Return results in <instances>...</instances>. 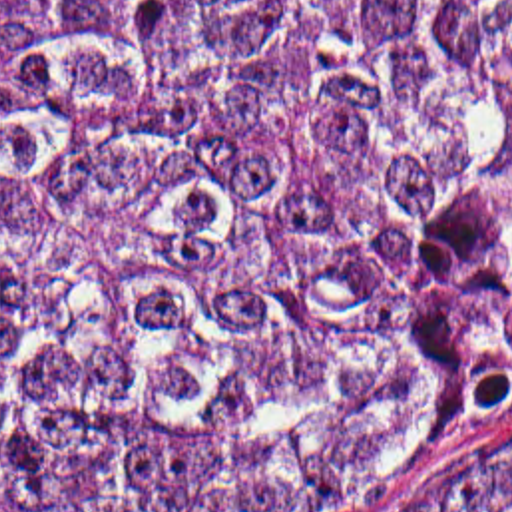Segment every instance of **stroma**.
<instances>
[{
	"label": "stroma",
	"instance_id": "stroma-1",
	"mask_svg": "<svg viewBox=\"0 0 512 512\" xmlns=\"http://www.w3.org/2000/svg\"><path fill=\"white\" fill-rule=\"evenodd\" d=\"M510 465L512 424L452 437L359 512H432L454 491Z\"/></svg>",
	"mask_w": 512,
	"mask_h": 512
}]
</instances>
